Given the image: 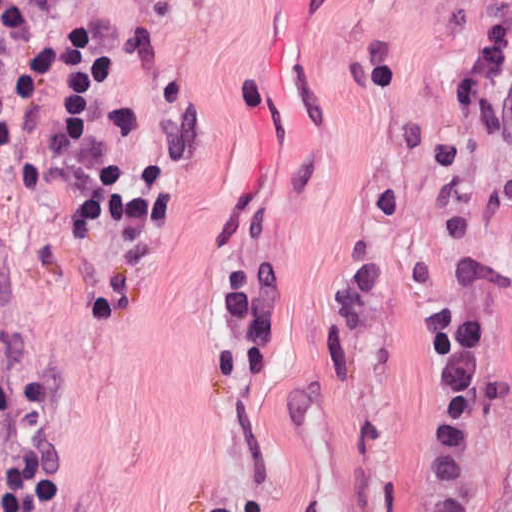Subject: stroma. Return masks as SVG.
<instances>
[{
    "label": "stroma",
    "mask_w": 512,
    "mask_h": 512,
    "mask_svg": "<svg viewBox=\"0 0 512 512\" xmlns=\"http://www.w3.org/2000/svg\"><path fill=\"white\" fill-rule=\"evenodd\" d=\"M91 169L0 161V352L45 370L46 512H413L425 316L495 307L512 384V142L454 87L512 0H63ZM468 508L512 512V390Z\"/></svg>",
    "instance_id": "35a3bbf8"
}]
</instances>
